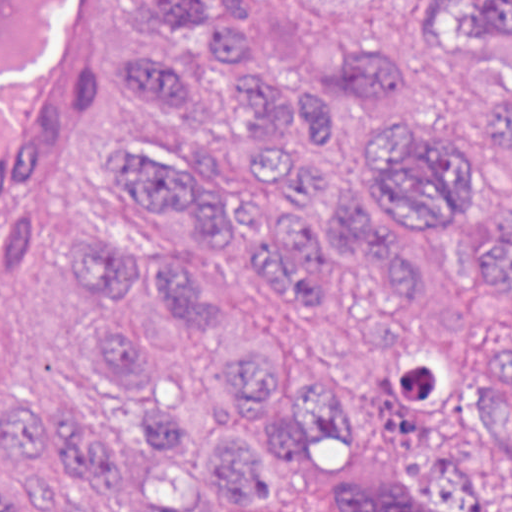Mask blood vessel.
I'll list each match as a JSON object with an SVG mask.
<instances>
[{"instance_id":"blood-vessel-1","label":"blood vessel","mask_w":512,"mask_h":512,"mask_svg":"<svg viewBox=\"0 0 512 512\" xmlns=\"http://www.w3.org/2000/svg\"><path fill=\"white\" fill-rule=\"evenodd\" d=\"M86 0H0V169L57 77Z\"/></svg>"}]
</instances>
